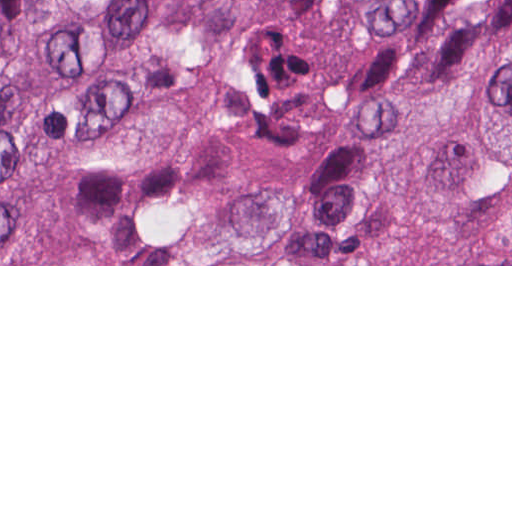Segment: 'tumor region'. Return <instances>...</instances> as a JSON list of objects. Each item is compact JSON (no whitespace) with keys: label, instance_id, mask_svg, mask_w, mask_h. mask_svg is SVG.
<instances>
[{"label":"tumor region","instance_id":"e687c5a6","mask_svg":"<svg viewBox=\"0 0 512 512\" xmlns=\"http://www.w3.org/2000/svg\"><path fill=\"white\" fill-rule=\"evenodd\" d=\"M68 192L115 263L512 265V0H0V264Z\"/></svg>","mask_w":512,"mask_h":512}]
</instances>
